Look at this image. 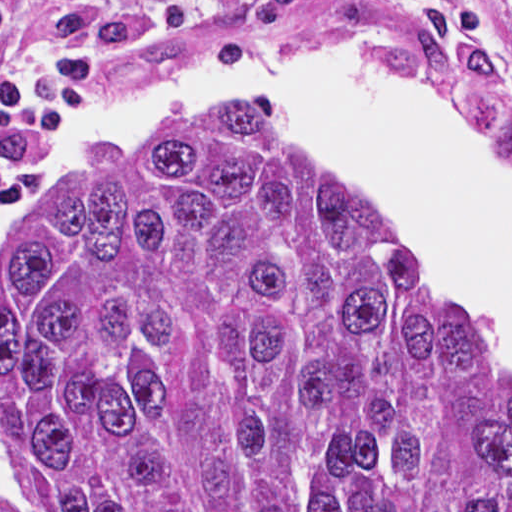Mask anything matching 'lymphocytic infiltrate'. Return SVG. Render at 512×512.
<instances>
[{
  "mask_svg": "<svg viewBox=\"0 0 512 512\" xmlns=\"http://www.w3.org/2000/svg\"><path fill=\"white\" fill-rule=\"evenodd\" d=\"M224 19V0H0V132L37 138L116 67L207 45Z\"/></svg>",
  "mask_w": 512,
  "mask_h": 512,
  "instance_id": "1",
  "label": "lymphocytic infiltrate"
}]
</instances>
